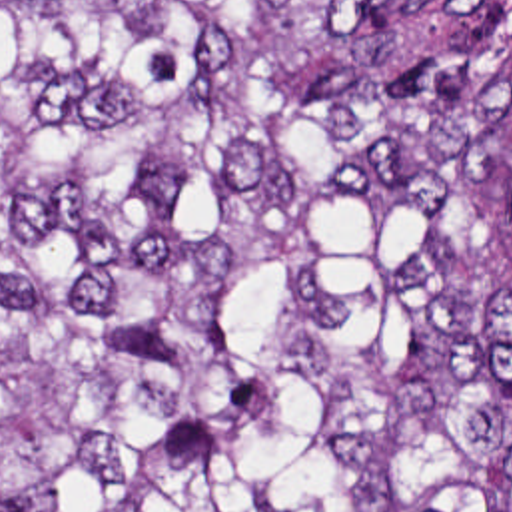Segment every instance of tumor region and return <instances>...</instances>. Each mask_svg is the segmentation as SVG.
Returning a JSON list of instances; mask_svg holds the SVG:
<instances>
[{
	"label": "tumor region",
	"instance_id": "tumor-region-1",
	"mask_svg": "<svg viewBox=\"0 0 512 512\" xmlns=\"http://www.w3.org/2000/svg\"><path fill=\"white\" fill-rule=\"evenodd\" d=\"M0 512H512V0H0Z\"/></svg>",
	"mask_w": 512,
	"mask_h": 512
}]
</instances>
